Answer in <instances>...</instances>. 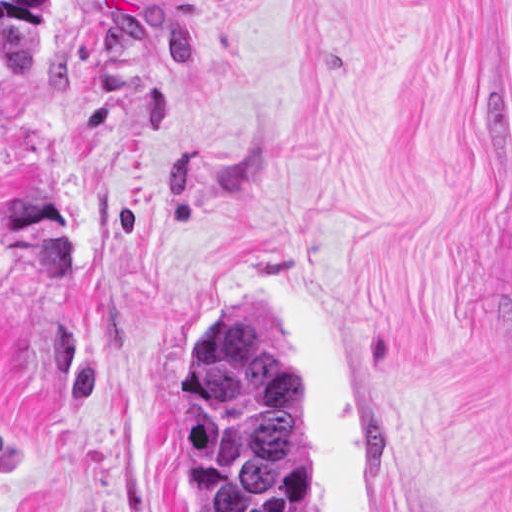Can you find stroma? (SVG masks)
I'll use <instances>...</instances> for the list:
<instances>
[{"mask_svg":"<svg viewBox=\"0 0 512 512\" xmlns=\"http://www.w3.org/2000/svg\"><path fill=\"white\" fill-rule=\"evenodd\" d=\"M321 293L387 512H512V0H51L0 43V512H196L177 345Z\"/></svg>","mask_w":512,"mask_h":512,"instance_id":"stroma-1","label":"stroma"}]
</instances>
